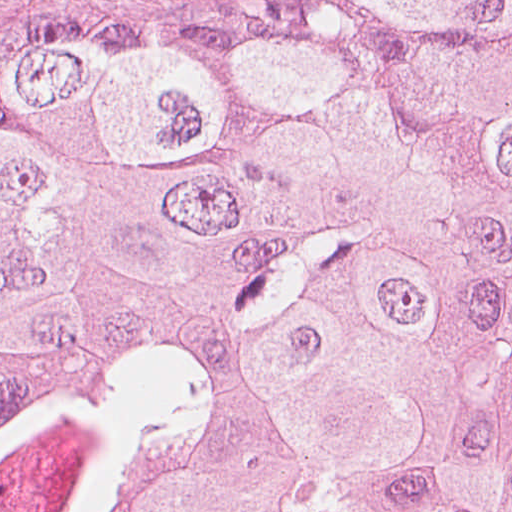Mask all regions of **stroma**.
Instances as JSON below:
<instances>
[{
	"label": "stroma",
	"instance_id": "stroma-1",
	"mask_svg": "<svg viewBox=\"0 0 512 512\" xmlns=\"http://www.w3.org/2000/svg\"><path fill=\"white\" fill-rule=\"evenodd\" d=\"M228 0H0V81L49 57Z\"/></svg>",
	"mask_w": 512,
	"mask_h": 512
}]
</instances>
